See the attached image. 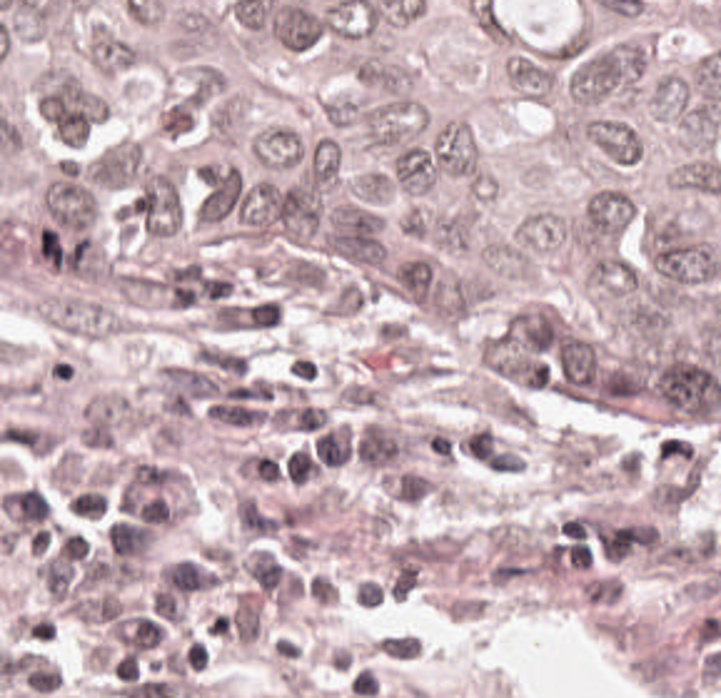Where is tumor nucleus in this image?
Returning <instances> with one entry per match:
<instances>
[{
  "instance_id": "tumor-nucleus-1",
  "label": "tumor nucleus",
  "mask_w": 721,
  "mask_h": 698,
  "mask_svg": "<svg viewBox=\"0 0 721 698\" xmlns=\"http://www.w3.org/2000/svg\"><path fill=\"white\" fill-rule=\"evenodd\" d=\"M631 217V198L622 191L599 189L588 206L581 227L586 237L607 242L625 230Z\"/></svg>"
}]
</instances>
